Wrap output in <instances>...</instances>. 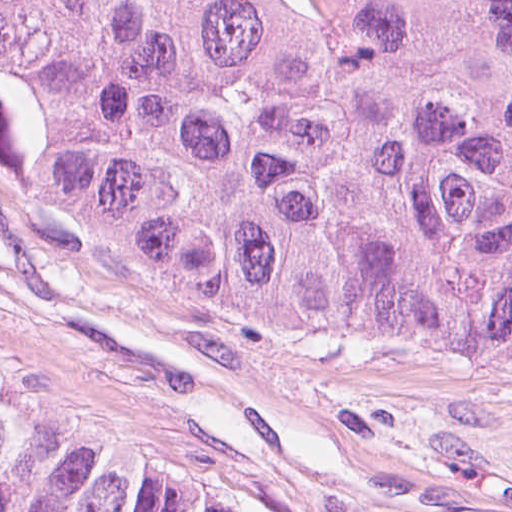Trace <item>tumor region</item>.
Masks as SVG:
<instances>
[{
  "instance_id": "e687c5a6",
  "label": "tumor region",
  "mask_w": 512,
  "mask_h": 512,
  "mask_svg": "<svg viewBox=\"0 0 512 512\" xmlns=\"http://www.w3.org/2000/svg\"><path fill=\"white\" fill-rule=\"evenodd\" d=\"M0 173L183 303L512 363V0H0ZM0 512L219 511L0 381Z\"/></svg>"
}]
</instances>
